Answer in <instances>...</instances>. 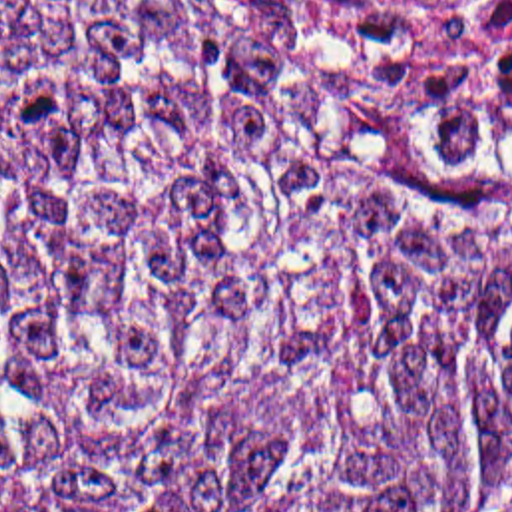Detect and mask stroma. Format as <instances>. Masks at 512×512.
<instances>
[{"label": "stroma", "mask_w": 512, "mask_h": 512, "mask_svg": "<svg viewBox=\"0 0 512 512\" xmlns=\"http://www.w3.org/2000/svg\"><path fill=\"white\" fill-rule=\"evenodd\" d=\"M128 7H140L160 13H172L182 17H223L231 21H241L257 27H267L297 35L321 45L335 47L379 71L377 59L383 41H345L329 33H323L305 23L303 15L295 7L293 0H108ZM506 99V97H502ZM454 127L462 129L502 171L512 175V165H508L482 137L476 121L466 115Z\"/></svg>", "instance_id": "obj_1"}]
</instances>
